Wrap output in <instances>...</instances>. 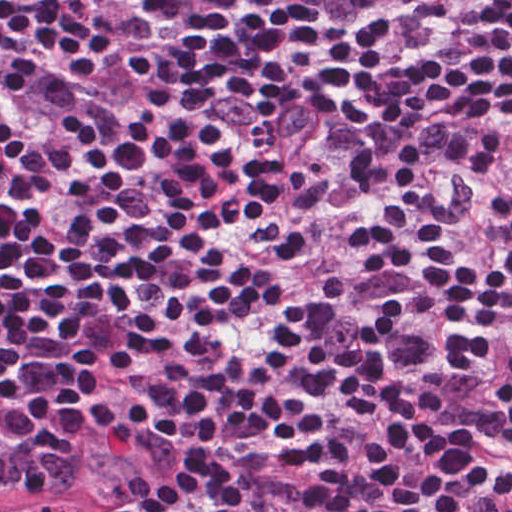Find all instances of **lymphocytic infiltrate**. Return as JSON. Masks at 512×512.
<instances>
[{
  "label": "lymphocytic infiltrate",
  "mask_w": 512,
  "mask_h": 512,
  "mask_svg": "<svg viewBox=\"0 0 512 512\" xmlns=\"http://www.w3.org/2000/svg\"><path fill=\"white\" fill-rule=\"evenodd\" d=\"M69 478L512 512V0H0V488Z\"/></svg>",
  "instance_id": "obj_1"
}]
</instances>
